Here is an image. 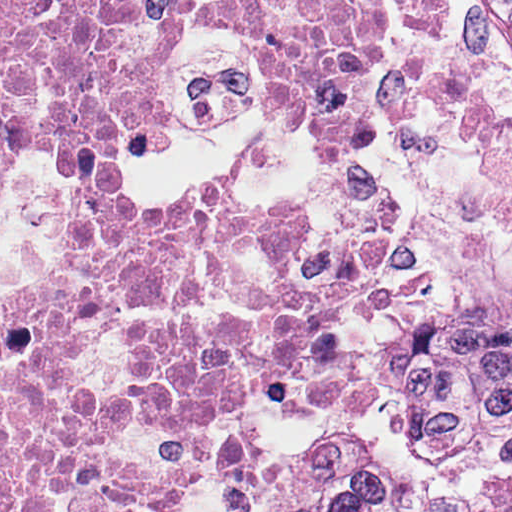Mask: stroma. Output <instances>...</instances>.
Listing matches in <instances>:
<instances>
[{
    "label": "stroma",
    "mask_w": 512,
    "mask_h": 512,
    "mask_svg": "<svg viewBox=\"0 0 512 512\" xmlns=\"http://www.w3.org/2000/svg\"><path fill=\"white\" fill-rule=\"evenodd\" d=\"M369 143L437 275L358 343L381 417L281 459L260 512L512 505V26L506 0H440V42L377 57Z\"/></svg>",
    "instance_id": "35a3bbf8"
}]
</instances>
